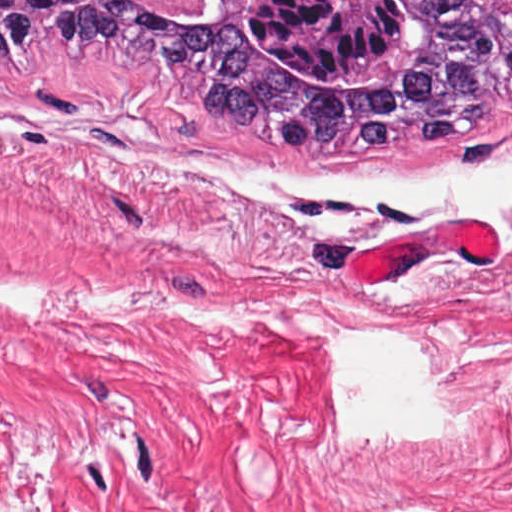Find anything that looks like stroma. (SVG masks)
Returning <instances> with one entry per match:
<instances>
[{"mask_svg":"<svg viewBox=\"0 0 512 512\" xmlns=\"http://www.w3.org/2000/svg\"><path fill=\"white\" fill-rule=\"evenodd\" d=\"M181 155L339 172L512 155V102L474 137L403 155L239 146L169 76L75 46L0 59V397L341 432L326 327L427 349L450 444L512 450V246L355 281L345 259L475 217L306 196L272 207ZM367 235L310 234L327 212ZM512 224V211L506 215Z\"/></svg>","mask_w":512,"mask_h":512,"instance_id":"35a3bbf8","label":"stroma"}]
</instances>
